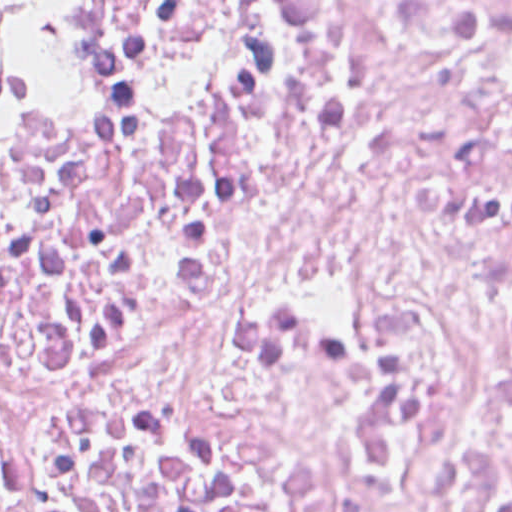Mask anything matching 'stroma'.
<instances>
[{
    "mask_svg": "<svg viewBox=\"0 0 512 512\" xmlns=\"http://www.w3.org/2000/svg\"><path fill=\"white\" fill-rule=\"evenodd\" d=\"M10 29V96L0 111V143L39 120L44 57L39 25L14 1L0 0Z\"/></svg>",
    "mask_w": 512,
    "mask_h": 512,
    "instance_id": "1",
    "label": "stroma"
}]
</instances>
